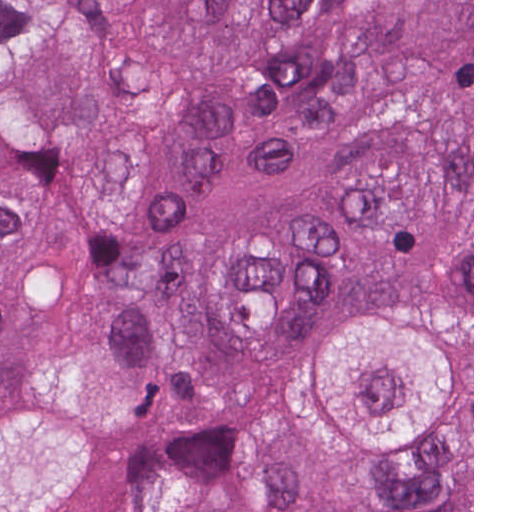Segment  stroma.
<instances>
[{
	"instance_id": "obj_1",
	"label": "stroma",
	"mask_w": 512,
	"mask_h": 512,
	"mask_svg": "<svg viewBox=\"0 0 512 512\" xmlns=\"http://www.w3.org/2000/svg\"><path fill=\"white\" fill-rule=\"evenodd\" d=\"M223 409L265 412L283 423L312 475L374 503H411L472 482L474 512V0H472V422L413 474L372 480L313 449L294 423L278 419L265 384H221L168 397L159 429L123 435L108 429L52 383L23 384L0 402V512H78L129 463L192 456L209 420Z\"/></svg>"
}]
</instances>
